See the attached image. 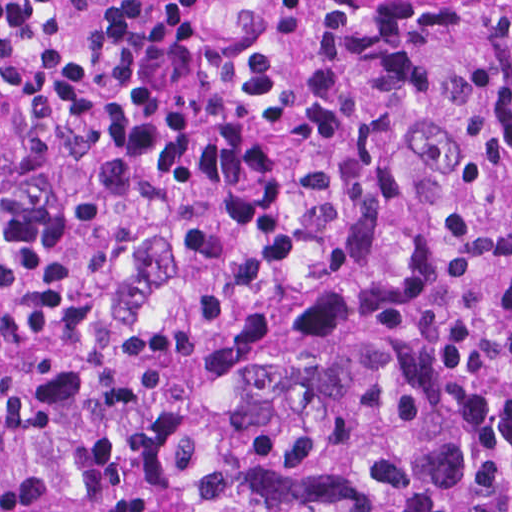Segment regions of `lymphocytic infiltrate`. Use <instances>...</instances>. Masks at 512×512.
Masks as SVG:
<instances>
[{"label": "lymphocytic infiltrate", "instance_id": "obj_1", "mask_svg": "<svg viewBox=\"0 0 512 512\" xmlns=\"http://www.w3.org/2000/svg\"><path fill=\"white\" fill-rule=\"evenodd\" d=\"M217 1L0 0V333L167 248L252 271L381 238L401 73L451 0H334L297 55L225 44Z\"/></svg>", "mask_w": 512, "mask_h": 512}]
</instances>
